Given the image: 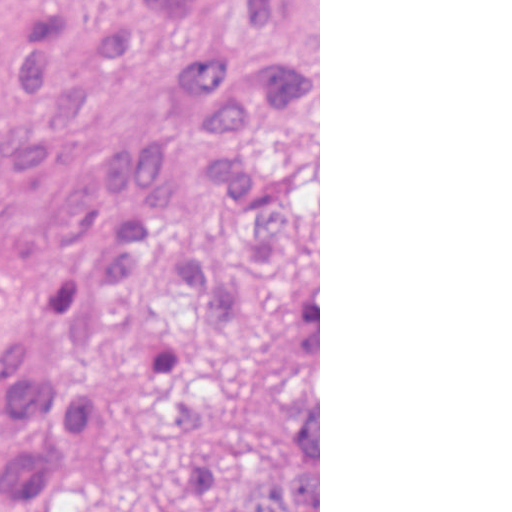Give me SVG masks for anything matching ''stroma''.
Here are the masks:
<instances>
[{
    "mask_svg": "<svg viewBox=\"0 0 512 512\" xmlns=\"http://www.w3.org/2000/svg\"><path fill=\"white\" fill-rule=\"evenodd\" d=\"M169 62L150 48L100 68L92 91L98 99L84 117L77 157L55 160L25 179L0 175V219L20 212L52 189L91 174L103 148L128 135L193 131L167 77ZM227 155L219 140L179 151L184 191L159 220L158 245L135 280H110L95 304L116 329L160 333L175 315L179 252L198 244H227L254 274H281L315 267L294 259H318L319 293V512H320V0H319V205L292 223L270 249L250 247L226 190L201 177V165ZM12 442L3 429L0 450ZM93 512H191V465L172 411L160 389L127 407L124 446L93 490Z\"/></svg>",
    "mask_w": 512,
    "mask_h": 512,
    "instance_id": "stroma-1",
    "label": "stroma"
}]
</instances>
